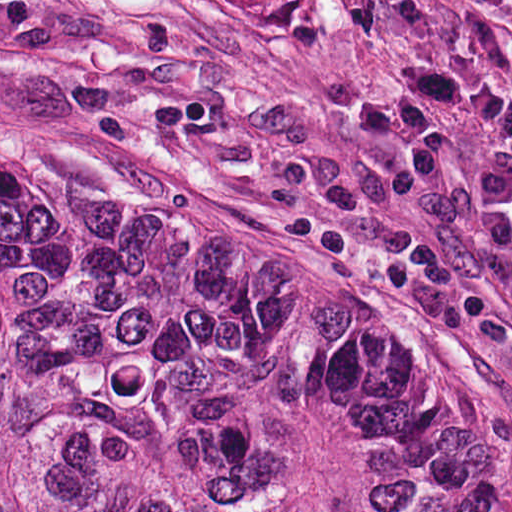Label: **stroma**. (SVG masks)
Segmentation results:
<instances>
[{"instance_id": "1", "label": "stroma", "mask_w": 512, "mask_h": 512, "mask_svg": "<svg viewBox=\"0 0 512 512\" xmlns=\"http://www.w3.org/2000/svg\"><path fill=\"white\" fill-rule=\"evenodd\" d=\"M422 53L272 0H0V132L63 134L370 319L512 468V248L467 183L512 143L443 111L424 175L342 114Z\"/></svg>"}]
</instances>
